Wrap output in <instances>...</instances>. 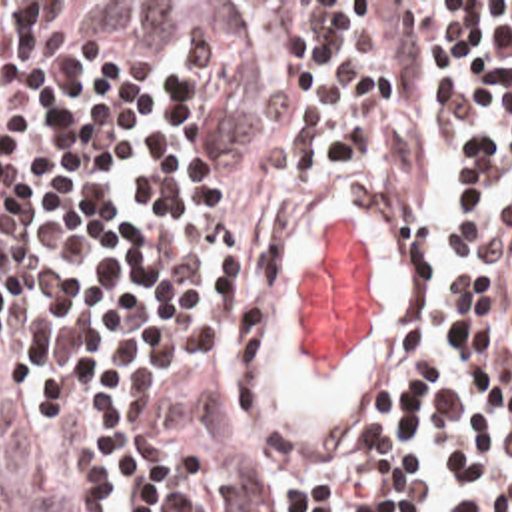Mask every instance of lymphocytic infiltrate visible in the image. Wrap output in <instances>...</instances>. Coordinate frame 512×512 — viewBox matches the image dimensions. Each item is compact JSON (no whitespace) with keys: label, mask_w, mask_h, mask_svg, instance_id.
Here are the masks:
<instances>
[{"label":"lymphocytic infiltrate","mask_w":512,"mask_h":512,"mask_svg":"<svg viewBox=\"0 0 512 512\" xmlns=\"http://www.w3.org/2000/svg\"><path fill=\"white\" fill-rule=\"evenodd\" d=\"M458 172L462 281L346 457L229 401L237 274L358 172ZM426 212V210H424ZM0 512H512V2H0Z\"/></svg>","instance_id":"obj_1"}]
</instances>
